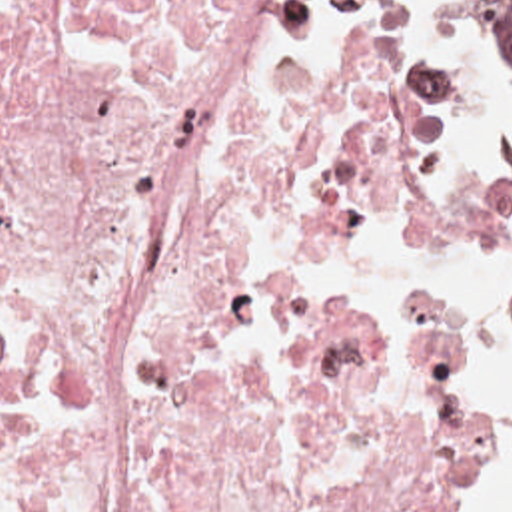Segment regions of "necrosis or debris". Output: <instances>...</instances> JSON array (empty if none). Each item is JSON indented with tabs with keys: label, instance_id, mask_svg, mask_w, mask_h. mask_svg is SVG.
Masks as SVG:
<instances>
[{
	"label": "necrosis or debris",
	"instance_id": "necrosis-or-debris-1",
	"mask_svg": "<svg viewBox=\"0 0 512 512\" xmlns=\"http://www.w3.org/2000/svg\"><path fill=\"white\" fill-rule=\"evenodd\" d=\"M455 217L431 113L315 0H0V512H463L487 323L345 309L297 203Z\"/></svg>",
	"mask_w": 512,
	"mask_h": 512
}]
</instances>
